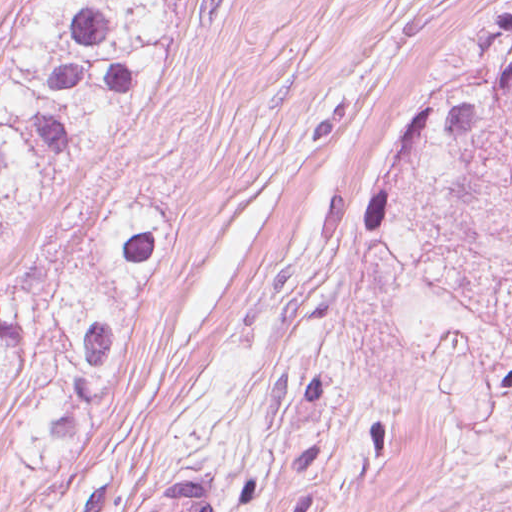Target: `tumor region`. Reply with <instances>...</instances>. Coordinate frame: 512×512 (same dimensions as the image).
<instances>
[{
	"mask_svg": "<svg viewBox=\"0 0 512 512\" xmlns=\"http://www.w3.org/2000/svg\"><path fill=\"white\" fill-rule=\"evenodd\" d=\"M183 0H28L0 49V248L91 181L160 82ZM512 107L442 84L369 195L382 230L421 165ZM179 244V209L99 193L56 217L0 291V399L22 405L18 456L60 468L105 425L118 373Z\"/></svg>",
	"mask_w": 512,
	"mask_h": 512,
	"instance_id": "e687c5a6",
	"label": "tumor region"
}]
</instances>
